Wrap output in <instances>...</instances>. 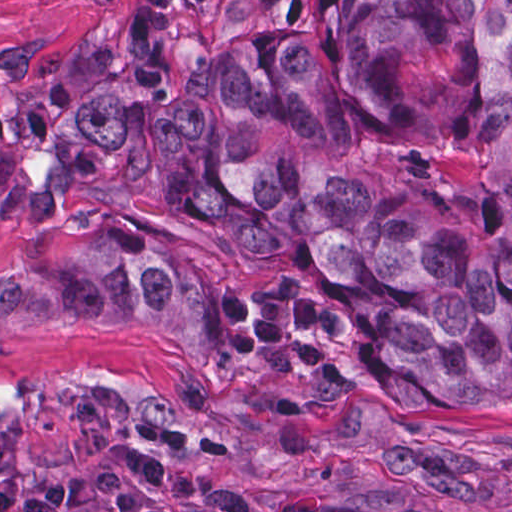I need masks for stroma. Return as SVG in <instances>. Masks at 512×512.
Here are the masks:
<instances>
[{
	"label": "stroma",
	"instance_id": "stroma-1",
	"mask_svg": "<svg viewBox=\"0 0 512 512\" xmlns=\"http://www.w3.org/2000/svg\"><path fill=\"white\" fill-rule=\"evenodd\" d=\"M129 0H0V109ZM185 37L282 27L327 0H189ZM134 245L222 292L300 295L314 262H259L209 218L151 198L0 217V270L42 238ZM126 440L163 446V489L206 512H512V398L360 391L291 408L194 382L181 350L119 327H46L0 343V512L68 494Z\"/></svg>",
	"mask_w": 512,
	"mask_h": 512
}]
</instances>
